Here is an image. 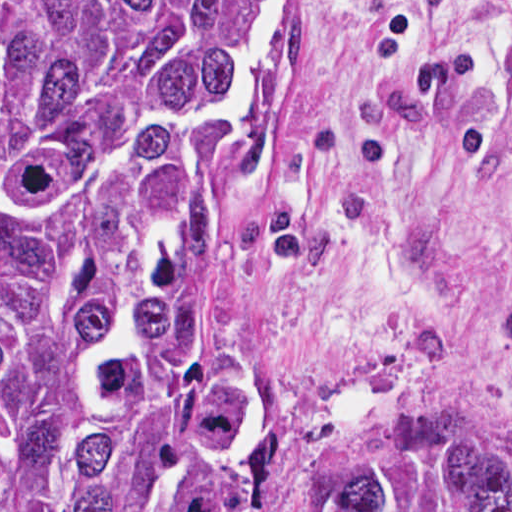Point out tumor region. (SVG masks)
Segmentation results:
<instances>
[{"label":"tumor region","mask_w":512,"mask_h":512,"mask_svg":"<svg viewBox=\"0 0 512 512\" xmlns=\"http://www.w3.org/2000/svg\"><path fill=\"white\" fill-rule=\"evenodd\" d=\"M244 0H1V512H512L429 442L253 450L203 276L254 122L224 117Z\"/></svg>","instance_id":"tumor-region-1"}]
</instances>
